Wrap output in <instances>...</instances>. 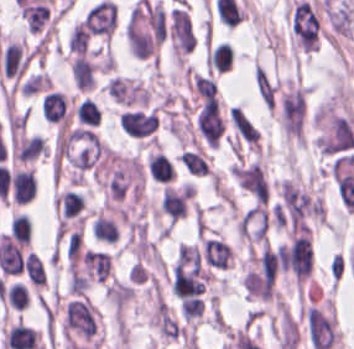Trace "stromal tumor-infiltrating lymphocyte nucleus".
I'll use <instances>...</instances> for the list:
<instances>
[{"mask_svg":"<svg viewBox=\"0 0 354 349\" xmlns=\"http://www.w3.org/2000/svg\"><path fill=\"white\" fill-rule=\"evenodd\" d=\"M181 161L190 173L199 176L209 173L207 159L199 146L181 151Z\"/></svg>","mask_w":354,"mask_h":349,"instance_id":"12","label":"stromal tumor-infiltrating lymphocyte nucleus"},{"mask_svg":"<svg viewBox=\"0 0 354 349\" xmlns=\"http://www.w3.org/2000/svg\"><path fill=\"white\" fill-rule=\"evenodd\" d=\"M96 66L83 55H75L70 66L73 82L78 90H89L94 84Z\"/></svg>","mask_w":354,"mask_h":349,"instance_id":"7","label":"stromal tumor-infiltrating lymphocyte nucleus"},{"mask_svg":"<svg viewBox=\"0 0 354 349\" xmlns=\"http://www.w3.org/2000/svg\"><path fill=\"white\" fill-rule=\"evenodd\" d=\"M291 30L298 42L308 51L317 47V15L307 0H300L291 11Z\"/></svg>","mask_w":354,"mask_h":349,"instance_id":"1","label":"stromal tumor-infiltrating lymphocyte nucleus"},{"mask_svg":"<svg viewBox=\"0 0 354 349\" xmlns=\"http://www.w3.org/2000/svg\"><path fill=\"white\" fill-rule=\"evenodd\" d=\"M5 300L8 305L21 310L28 305V290L15 280L6 285Z\"/></svg>","mask_w":354,"mask_h":349,"instance_id":"15","label":"stromal tumor-infiltrating lymphocyte nucleus"},{"mask_svg":"<svg viewBox=\"0 0 354 349\" xmlns=\"http://www.w3.org/2000/svg\"><path fill=\"white\" fill-rule=\"evenodd\" d=\"M50 87V79L43 72L30 74L19 86L18 92L25 96L33 95Z\"/></svg>","mask_w":354,"mask_h":349,"instance_id":"14","label":"stromal tumor-infiltrating lymphocyte nucleus"},{"mask_svg":"<svg viewBox=\"0 0 354 349\" xmlns=\"http://www.w3.org/2000/svg\"><path fill=\"white\" fill-rule=\"evenodd\" d=\"M196 126L204 142L218 147L223 130V117L217 97H208L196 113Z\"/></svg>","mask_w":354,"mask_h":349,"instance_id":"2","label":"stromal tumor-infiltrating lymphocyte nucleus"},{"mask_svg":"<svg viewBox=\"0 0 354 349\" xmlns=\"http://www.w3.org/2000/svg\"><path fill=\"white\" fill-rule=\"evenodd\" d=\"M11 237L28 244L31 238V224L29 217L24 213H17L10 222Z\"/></svg>","mask_w":354,"mask_h":349,"instance_id":"16","label":"stromal tumor-infiltrating lymphocyte nucleus"},{"mask_svg":"<svg viewBox=\"0 0 354 349\" xmlns=\"http://www.w3.org/2000/svg\"><path fill=\"white\" fill-rule=\"evenodd\" d=\"M203 299L185 298L180 301V312L182 319L191 321L202 314Z\"/></svg>","mask_w":354,"mask_h":349,"instance_id":"17","label":"stromal tumor-infiltrating lymphocyte nucleus"},{"mask_svg":"<svg viewBox=\"0 0 354 349\" xmlns=\"http://www.w3.org/2000/svg\"><path fill=\"white\" fill-rule=\"evenodd\" d=\"M95 238L103 242H113L116 239L117 227L114 218L97 212L91 226Z\"/></svg>","mask_w":354,"mask_h":349,"instance_id":"10","label":"stromal tumor-infiltrating lymphocyte nucleus"},{"mask_svg":"<svg viewBox=\"0 0 354 349\" xmlns=\"http://www.w3.org/2000/svg\"><path fill=\"white\" fill-rule=\"evenodd\" d=\"M28 62L23 39L10 41L0 52V69L7 78H18Z\"/></svg>","mask_w":354,"mask_h":349,"instance_id":"4","label":"stromal tumor-infiltrating lymphocyte nucleus"},{"mask_svg":"<svg viewBox=\"0 0 354 349\" xmlns=\"http://www.w3.org/2000/svg\"><path fill=\"white\" fill-rule=\"evenodd\" d=\"M11 196L18 203L29 202L36 193V180L32 169L22 168L11 172Z\"/></svg>","mask_w":354,"mask_h":349,"instance_id":"5","label":"stromal tumor-infiltrating lymphocyte nucleus"},{"mask_svg":"<svg viewBox=\"0 0 354 349\" xmlns=\"http://www.w3.org/2000/svg\"><path fill=\"white\" fill-rule=\"evenodd\" d=\"M22 270L32 286L42 288L45 274L43 264L37 256L28 251L23 257Z\"/></svg>","mask_w":354,"mask_h":349,"instance_id":"11","label":"stromal tumor-infiltrating lymphocyte nucleus"},{"mask_svg":"<svg viewBox=\"0 0 354 349\" xmlns=\"http://www.w3.org/2000/svg\"><path fill=\"white\" fill-rule=\"evenodd\" d=\"M147 172L156 182H169L173 177V167L162 151H149L146 160Z\"/></svg>","mask_w":354,"mask_h":349,"instance_id":"8","label":"stromal tumor-infiltrating lymphocyte nucleus"},{"mask_svg":"<svg viewBox=\"0 0 354 349\" xmlns=\"http://www.w3.org/2000/svg\"><path fill=\"white\" fill-rule=\"evenodd\" d=\"M100 114L101 111L96 102L85 98L74 107V116L82 124L98 125Z\"/></svg>","mask_w":354,"mask_h":349,"instance_id":"13","label":"stromal tumor-infiltrating lymphocyte nucleus"},{"mask_svg":"<svg viewBox=\"0 0 354 349\" xmlns=\"http://www.w3.org/2000/svg\"><path fill=\"white\" fill-rule=\"evenodd\" d=\"M56 204L62 217H75L84 206V197L75 191L63 190L56 196Z\"/></svg>","mask_w":354,"mask_h":349,"instance_id":"9","label":"stromal tumor-infiltrating lymphocyte nucleus"},{"mask_svg":"<svg viewBox=\"0 0 354 349\" xmlns=\"http://www.w3.org/2000/svg\"><path fill=\"white\" fill-rule=\"evenodd\" d=\"M82 262L88 279L103 282L110 270L109 253L87 249L83 252Z\"/></svg>","mask_w":354,"mask_h":349,"instance_id":"6","label":"stromal tumor-infiltrating lymphocyte nucleus"},{"mask_svg":"<svg viewBox=\"0 0 354 349\" xmlns=\"http://www.w3.org/2000/svg\"><path fill=\"white\" fill-rule=\"evenodd\" d=\"M119 123L125 133L143 137L156 129L157 114L152 110L125 109L119 114Z\"/></svg>","mask_w":354,"mask_h":349,"instance_id":"3","label":"stromal tumor-infiltrating lymphocyte nucleus"}]
</instances>
